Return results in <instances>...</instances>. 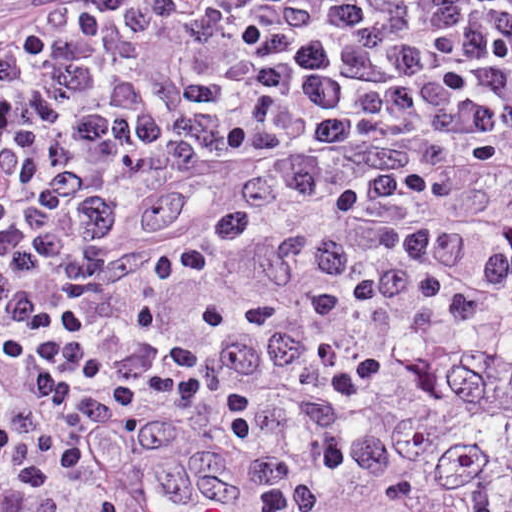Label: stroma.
<instances>
[{
	"instance_id": "35a3bbf8",
	"label": "stroma",
	"mask_w": 512,
	"mask_h": 512,
	"mask_svg": "<svg viewBox=\"0 0 512 512\" xmlns=\"http://www.w3.org/2000/svg\"><path fill=\"white\" fill-rule=\"evenodd\" d=\"M511 324L512 322L508 319V315L487 320L483 324L461 335L449 345H463L493 330ZM384 393L377 397L363 412L373 406ZM19 486L20 482L17 474L8 470L0 469V512H13V501Z\"/></svg>"
}]
</instances>
